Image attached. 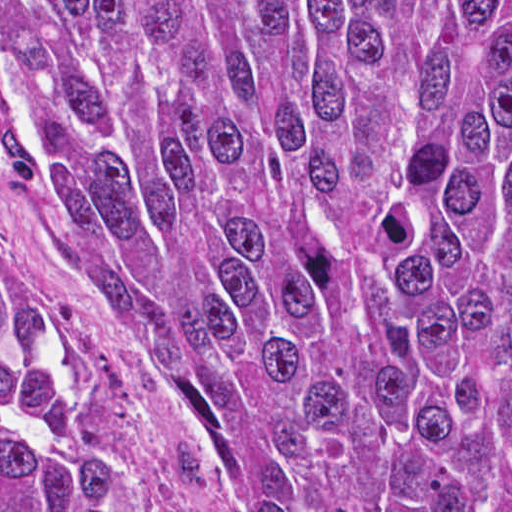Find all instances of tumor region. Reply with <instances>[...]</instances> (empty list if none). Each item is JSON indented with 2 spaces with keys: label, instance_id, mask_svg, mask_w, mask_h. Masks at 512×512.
I'll return each instance as SVG.
<instances>
[{
  "label": "tumor region",
  "instance_id": "tumor-region-1",
  "mask_svg": "<svg viewBox=\"0 0 512 512\" xmlns=\"http://www.w3.org/2000/svg\"><path fill=\"white\" fill-rule=\"evenodd\" d=\"M0 73L252 512H512V0H0ZM0 512H170L2 243Z\"/></svg>",
  "mask_w": 512,
  "mask_h": 512
}]
</instances>
